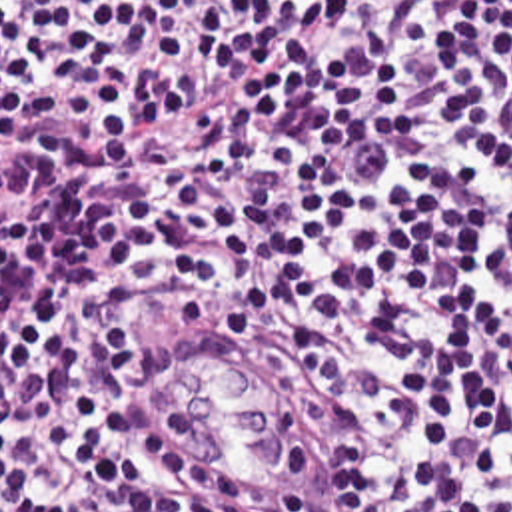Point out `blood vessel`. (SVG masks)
<instances>
[{
	"mask_svg": "<svg viewBox=\"0 0 512 512\" xmlns=\"http://www.w3.org/2000/svg\"><path fill=\"white\" fill-rule=\"evenodd\" d=\"M230 344L166 318L152 360L170 444L192 481L256 509L314 511L329 471L324 424L242 374Z\"/></svg>",
	"mask_w": 512,
	"mask_h": 512,
	"instance_id": "blood-vessel-1",
	"label": "blood vessel"
}]
</instances>
